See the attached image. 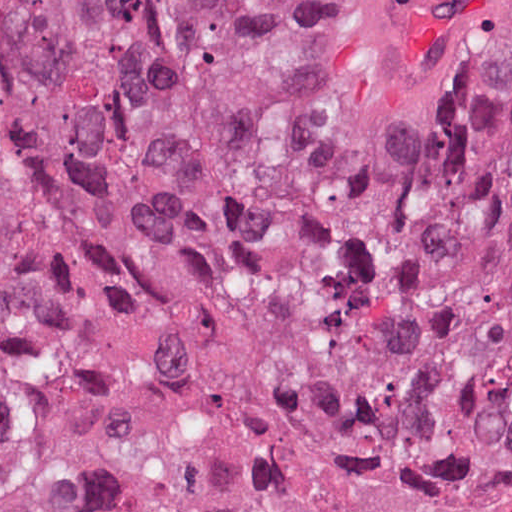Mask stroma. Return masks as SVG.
Returning a JSON list of instances; mask_svg holds the SVG:
<instances>
[{
    "label": "stroma",
    "instance_id": "obj_1",
    "mask_svg": "<svg viewBox=\"0 0 512 512\" xmlns=\"http://www.w3.org/2000/svg\"><path fill=\"white\" fill-rule=\"evenodd\" d=\"M376 1L318 0L304 29L300 51L282 96L274 162L284 133L294 129L320 134L335 147L347 71L364 22ZM511 99L512 50L488 88L467 109L371 171L406 184L413 192L414 201L396 225L371 246L355 253L339 298L362 264L396 235L414 213L432 203L474 162L488 144ZM30 311L61 328H71L54 317ZM0 364L14 363L0 358ZM91 473L100 500L92 430Z\"/></svg>",
    "mask_w": 512,
    "mask_h": 512
}]
</instances>
